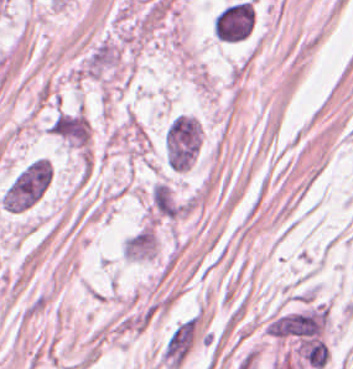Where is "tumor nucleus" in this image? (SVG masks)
<instances>
[{
  "label": "tumor nucleus",
  "instance_id": "obj_1",
  "mask_svg": "<svg viewBox=\"0 0 353 369\" xmlns=\"http://www.w3.org/2000/svg\"><path fill=\"white\" fill-rule=\"evenodd\" d=\"M52 169L44 156L24 164L4 187L0 201L12 212H21L37 202L44 192Z\"/></svg>",
  "mask_w": 353,
  "mask_h": 369
},
{
  "label": "tumor nucleus",
  "instance_id": "obj_2",
  "mask_svg": "<svg viewBox=\"0 0 353 369\" xmlns=\"http://www.w3.org/2000/svg\"><path fill=\"white\" fill-rule=\"evenodd\" d=\"M199 128L195 116L173 115L162 133V149L168 167L187 169L198 152Z\"/></svg>",
  "mask_w": 353,
  "mask_h": 369
},
{
  "label": "tumor nucleus",
  "instance_id": "obj_3",
  "mask_svg": "<svg viewBox=\"0 0 353 369\" xmlns=\"http://www.w3.org/2000/svg\"><path fill=\"white\" fill-rule=\"evenodd\" d=\"M254 18V5L249 0L228 2L214 13L212 32L222 42H236L248 36Z\"/></svg>",
  "mask_w": 353,
  "mask_h": 369
}]
</instances>
